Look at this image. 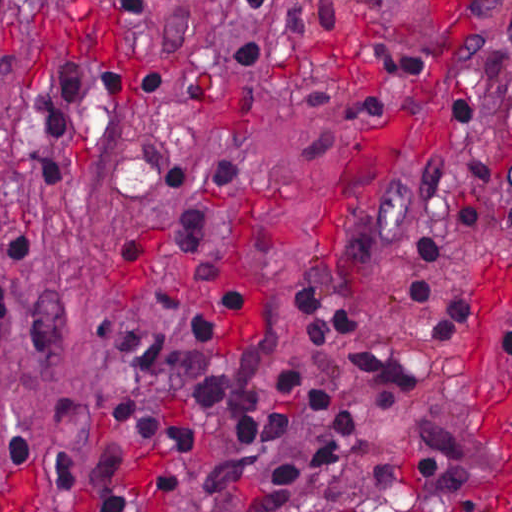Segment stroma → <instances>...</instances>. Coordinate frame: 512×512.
I'll return each instance as SVG.
<instances>
[{"label":"stroma","instance_id":"stroma-1","mask_svg":"<svg viewBox=\"0 0 512 512\" xmlns=\"http://www.w3.org/2000/svg\"><path fill=\"white\" fill-rule=\"evenodd\" d=\"M238 0H7L0 27V220L34 216L53 242L12 328L0 343V483L34 473V512H91L90 476L107 416L122 385L103 338L130 317L163 339L230 353L259 334L304 372L315 373L361 414L353 437L304 422L255 471L276 470L324 442L333 467L305 482L282 512H512L495 495L483 434V394L511 340L512 0L455 8L446 0H279V67L232 71L231 51L272 42L237 11ZM155 50L212 86L219 102L150 101L128 59L143 31ZM389 69L393 97L341 139L333 168H303L309 140L338 137L294 99L298 72L359 78ZM118 72L126 113L113 129L51 136L40 153L80 176L76 188L28 190L27 142L57 94ZM467 100L492 137V202L476 240L456 221L465 148L430 106ZM420 136L452 163L444 195L429 207L397 194L423 172ZM148 144H179L236 158L252 177L197 254L161 244L178 209L144 158ZM472 245L456 266L423 260L416 235ZM127 236L145 239L131 272ZM244 286L245 310L211 339L171 315L136 306V292L173 290L201 306L213 292L195 273L226 245ZM410 274L454 275L474 314L442 342L423 341L422 315L403 287ZM330 292L363 323L317 351L294 317L295 291ZM388 350L440 360L453 370L407 392H376L348 371L347 353ZM161 413L201 428L195 449H164L160 464L185 479L160 495L150 450L135 459V512H244L208 456L211 422L182 401ZM71 453L75 488L51 498L38 454Z\"/></svg>","mask_w":512,"mask_h":512}]
</instances>
